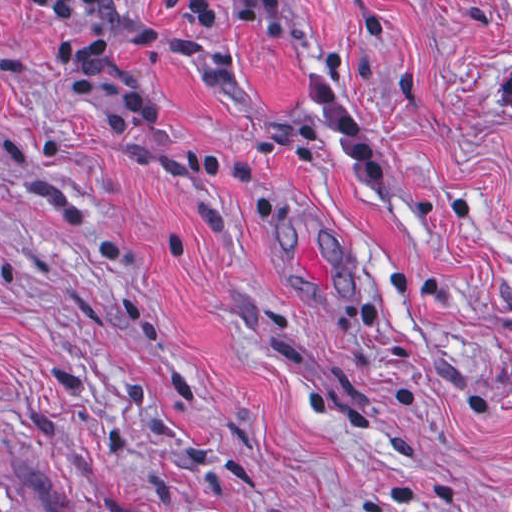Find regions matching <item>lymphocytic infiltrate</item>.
I'll use <instances>...</instances> for the list:
<instances>
[{
	"label": "lymphocytic infiltrate",
	"instance_id": "1",
	"mask_svg": "<svg viewBox=\"0 0 512 512\" xmlns=\"http://www.w3.org/2000/svg\"><path fill=\"white\" fill-rule=\"evenodd\" d=\"M38 5L53 26V50L63 78L112 125H144L156 111L153 99L130 78L134 48L173 56L209 37L219 14L211 0L192 2L181 24L141 31L125 0H25ZM237 12L265 25H282L292 0H226Z\"/></svg>",
	"mask_w": 512,
	"mask_h": 512
}]
</instances>
